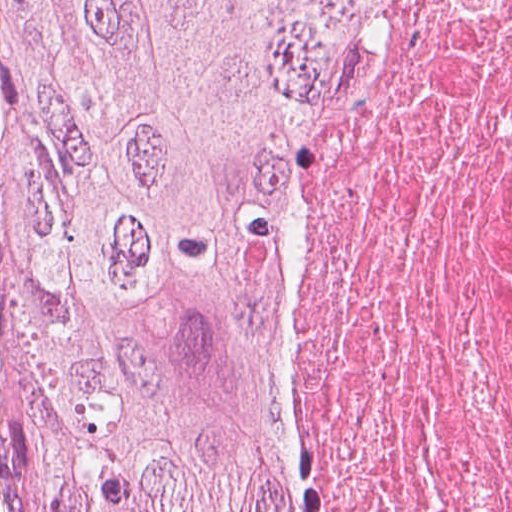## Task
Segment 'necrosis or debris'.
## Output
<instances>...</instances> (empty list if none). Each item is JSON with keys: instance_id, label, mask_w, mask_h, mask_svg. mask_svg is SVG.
I'll list each match as a JSON object with an SVG mask.
<instances>
[{"instance_id": "4bbe7bcc", "label": "necrosis or debris", "mask_w": 512, "mask_h": 512, "mask_svg": "<svg viewBox=\"0 0 512 512\" xmlns=\"http://www.w3.org/2000/svg\"><path fill=\"white\" fill-rule=\"evenodd\" d=\"M252 363L296 512H512V0L331 68Z\"/></svg>"}]
</instances>
